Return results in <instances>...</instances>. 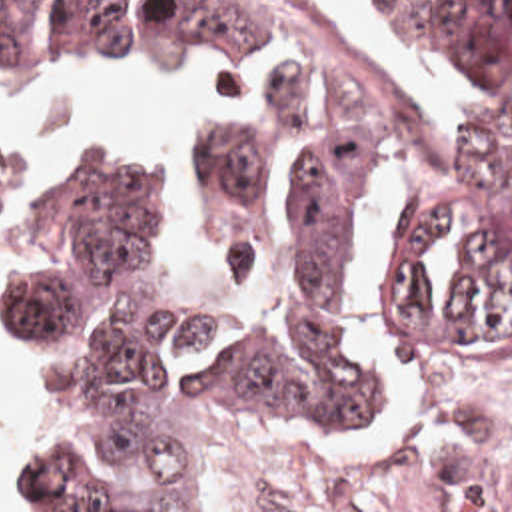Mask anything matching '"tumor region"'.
<instances>
[{"mask_svg":"<svg viewBox=\"0 0 512 512\" xmlns=\"http://www.w3.org/2000/svg\"><path fill=\"white\" fill-rule=\"evenodd\" d=\"M470 69L512 115V0H382ZM220 51L252 73L288 57L274 133L230 129L208 201L240 237H288V305L260 340L132 295L164 219L150 179L89 143L23 209L5 253L0 348L71 342L93 366V438L25 434L37 512H214L206 416L224 396H298L378 428L388 404L368 346L378 265L400 362L460 390H512V149L488 127L426 159L352 59L290 0H0V59L23 71L144 69Z\"/></svg>","mask_w":512,"mask_h":512,"instance_id":"obj_1","label":"tumor region"}]
</instances>
